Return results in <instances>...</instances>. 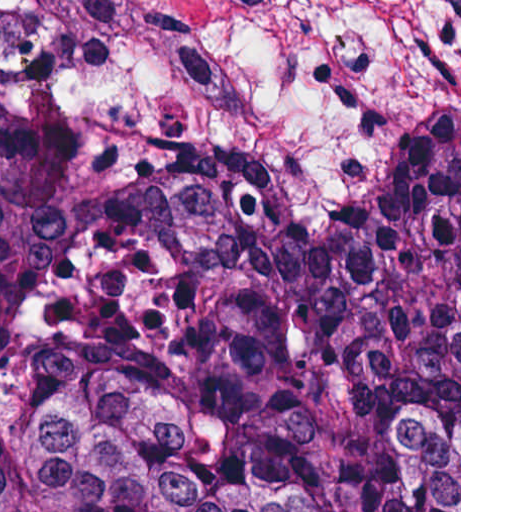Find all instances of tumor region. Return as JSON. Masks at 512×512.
<instances>
[{
	"mask_svg": "<svg viewBox=\"0 0 512 512\" xmlns=\"http://www.w3.org/2000/svg\"><path fill=\"white\" fill-rule=\"evenodd\" d=\"M0 512H459L441 158L355 283L210 168L93 199L0 75Z\"/></svg>",
	"mask_w": 512,
	"mask_h": 512,
	"instance_id": "e687c5a6",
	"label": "tumor region"
}]
</instances>
